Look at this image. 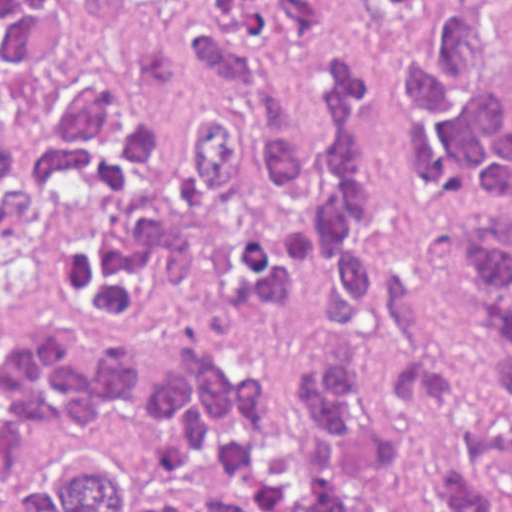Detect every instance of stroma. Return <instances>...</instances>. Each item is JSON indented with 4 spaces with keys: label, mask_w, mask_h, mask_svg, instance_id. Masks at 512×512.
<instances>
[{
    "label": "stroma",
    "mask_w": 512,
    "mask_h": 512,
    "mask_svg": "<svg viewBox=\"0 0 512 512\" xmlns=\"http://www.w3.org/2000/svg\"><path fill=\"white\" fill-rule=\"evenodd\" d=\"M510 38L502 79L512 88V0H499ZM446 4L424 0L417 12L368 16L350 0H336L338 32L326 47L282 53L279 72L307 148L321 134L324 53L343 40L359 55L369 92V134L392 184L379 219L365 228L369 247L413 290V334L401 350L340 343L321 330V262L305 252L298 295L283 306L244 299L229 309L191 295L187 274L166 264L153 278L149 299L130 306L92 291L52 299L1 294V0H0V512H59L54 485L1 462V341L48 326L92 322L105 337H153L186 326H211L266 364L309 352H364L380 360L435 370L456 367V346L444 292V247L471 211L486 207L452 193L430 197L408 166L400 125L396 54L434 43Z\"/></svg>",
    "instance_id": "35a3bbf8"
}]
</instances>
